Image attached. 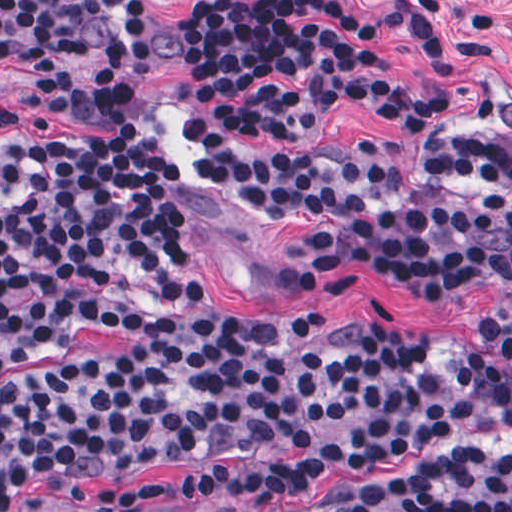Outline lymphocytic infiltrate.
Listing matches in <instances>:
<instances>
[{
  "label": "lymphocytic infiltrate",
  "mask_w": 512,
  "mask_h": 512,
  "mask_svg": "<svg viewBox=\"0 0 512 512\" xmlns=\"http://www.w3.org/2000/svg\"><path fill=\"white\" fill-rule=\"evenodd\" d=\"M457 1H201L178 121L208 184L272 238L328 266L512 297V142L456 136L413 171L366 140H305L330 106L410 130L446 108L396 82L404 25L434 73L491 57L442 20ZM154 12L127 1H0V78L144 59ZM153 80L39 77L22 91L71 136L0 113V369L114 329L128 352L0 389V512L45 477L99 512L171 496L141 465H189L183 492L268 510L336 477L512 436V356L476 331L319 319L257 328L220 311L200 249L171 226L189 196ZM344 512H512V448L464 451L368 488Z\"/></svg>",
  "instance_id": "lymphocytic-infiltrate-1"
}]
</instances>
